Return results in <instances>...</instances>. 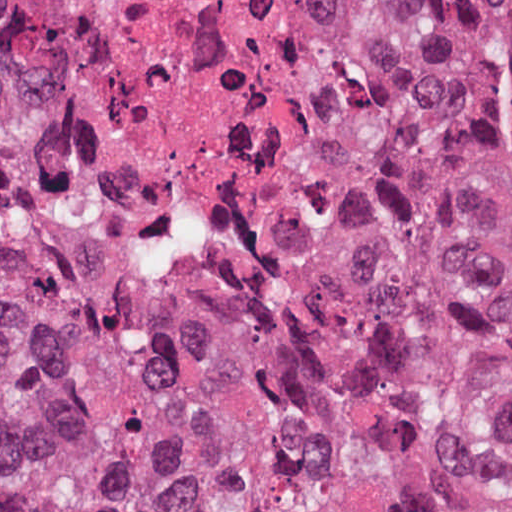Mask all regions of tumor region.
I'll return each mask as SVG.
<instances>
[{
    "label": "tumor region",
    "instance_id": "1",
    "mask_svg": "<svg viewBox=\"0 0 512 512\" xmlns=\"http://www.w3.org/2000/svg\"><path fill=\"white\" fill-rule=\"evenodd\" d=\"M318 243L512 299V0H346ZM0 512H512V364L185 285L0 104Z\"/></svg>",
    "mask_w": 512,
    "mask_h": 512
}]
</instances>
